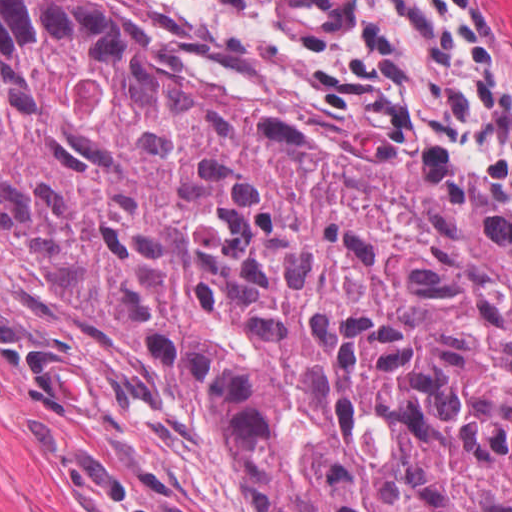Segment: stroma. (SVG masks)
<instances>
[{"mask_svg": "<svg viewBox=\"0 0 512 512\" xmlns=\"http://www.w3.org/2000/svg\"><path fill=\"white\" fill-rule=\"evenodd\" d=\"M173 2L280 61L350 141H400L512 223V185L440 132L379 116L228 0ZM512 53V0H479ZM0 512H241L237 451L184 368L58 300L0 232Z\"/></svg>", "mask_w": 512, "mask_h": 512, "instance_id": "1", "label": "stroma"}]
</instances>
